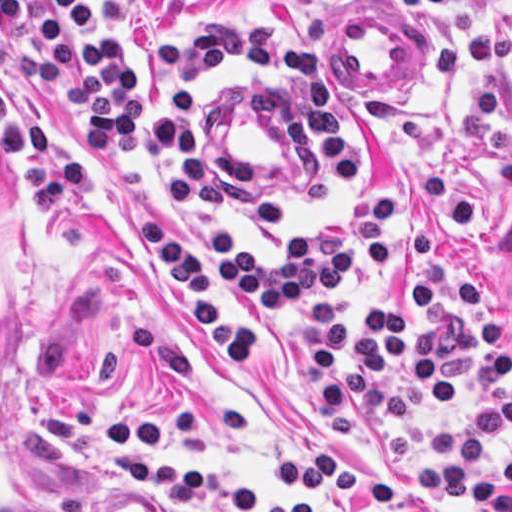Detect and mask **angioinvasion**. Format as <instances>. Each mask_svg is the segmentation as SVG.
<instances>
[{"mask_svg":"<svg viewBox=\"0 0 512 512\" xmlns=\"http://www.w3.org/2000/svg\"><path fill=\"white\" fill-rule=\"evenodd\" d=\"M24 251L0 192V512H71L51 477L25 404L20 309Z\"/></svg>","mask_w":512,"mask_h":512,"instance_id":"e142278d","label":"angioinvasion"}]
</instances>
